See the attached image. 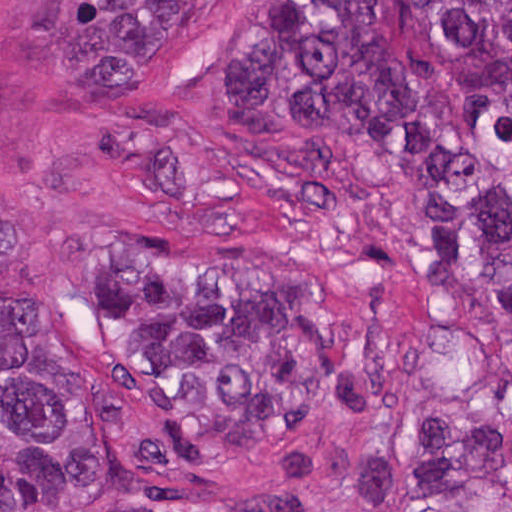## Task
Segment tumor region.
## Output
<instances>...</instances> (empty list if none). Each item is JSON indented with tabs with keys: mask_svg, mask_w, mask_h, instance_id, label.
Masks as SVG:
<instances>
[{
	"mask_svg": "<svg viewBox=\"0 0 512 512\" xmlns=\"http://www.w3.org/2000/svg\"><path fill=\"white\" fill-rule=\"evenodd\" d=\"M233 84L255 163L322 200L368 157L436 287L512 326V0H248ZM341 374L322 264L135 251L92 356L0 328V512L105 507L260 450L296 494L337 482L364 512H512V454L479 417L429 413L386 444L318 429Z\"/></svg>",
	"mask_w": 512,
	"mask_h": 512,
	"instance_id": "tumor-region-1",
	"label": "tumor region"
}]
</instances>
